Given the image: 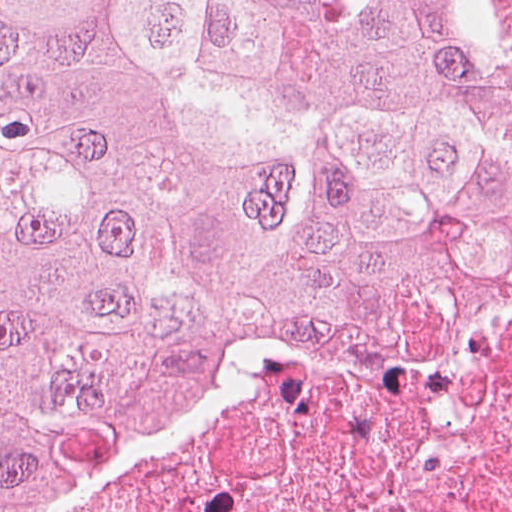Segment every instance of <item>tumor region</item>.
<instances>
[{
	"label": "tumor region",
	"instance_id": "tumor-region-1",
	"mask_svg": "<svg viewBox=\"0 0 512 512\" xmlns=\"http://www.w3.org/2000/svg\"><path fill=\"white\" fill-rule=\"evenodd\" d=\"M512 294V0H0V512Z\"/></svg>",
	"mask_w": 512,
	"mask_h": 512
}]
</instances>
